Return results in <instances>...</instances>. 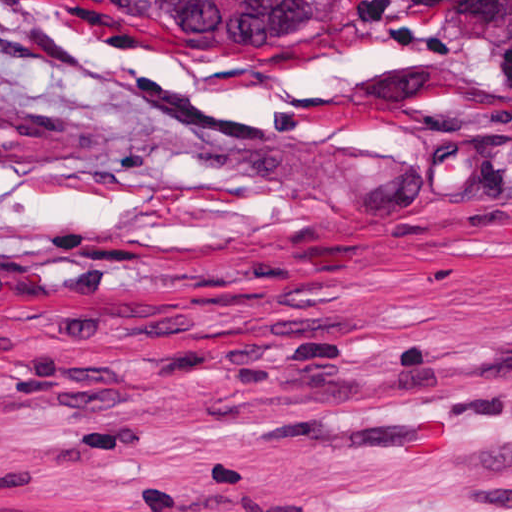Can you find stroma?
I'll return each instance as SVG.
<instances>
[{
    "label": "stroma",
    "instance_id": "stroma-1",
    "mask_svg": "<svg viewBox=\"0 0 512 512\" xmlns=\"http://www.w3.org/2000/svg\"><path fill=\"white\" fill-rule=\"evenodd\" d=\"M0 512H512V0H0Z\"/></svg>",
    "mask_w": 512,
    "mask_h": 512
}]
</instances>
